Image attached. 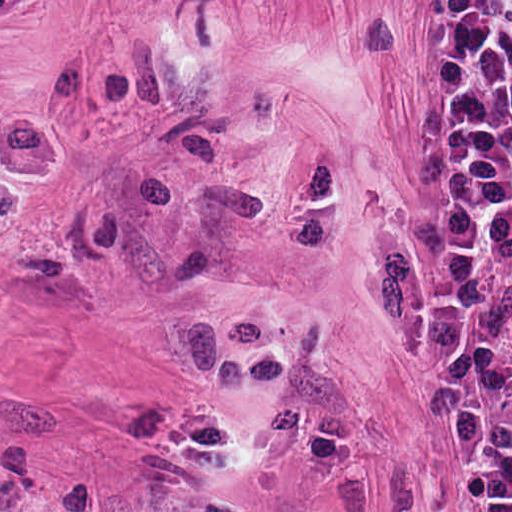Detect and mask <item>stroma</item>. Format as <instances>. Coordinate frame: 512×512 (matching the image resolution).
<instances>
[{"label": "stroma", "mask_w": 512, "mask_h": 512, "mask_svg": "<svg viewBox=\"0 0 512 512\" xmlns=\"http://www.w3.org/2000/svg\"><path fill=\"white\" fill-rule=\"evenodd\" d=\"M423 2L38 0L0 512H479L412 340Z\"/></svg>", "instance_id": "stroma-1"}]
</instances>
